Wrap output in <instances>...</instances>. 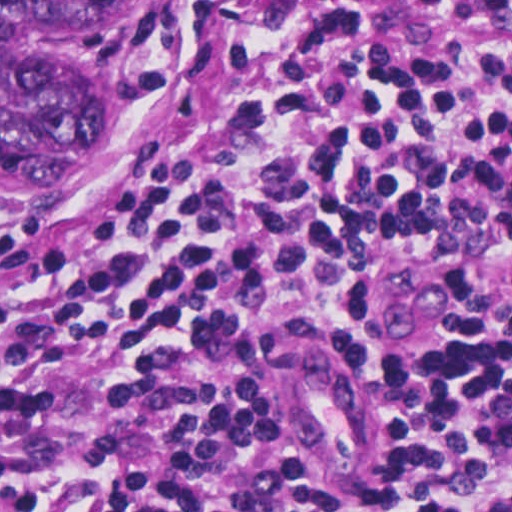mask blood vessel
I'll list each match as a JSON object with an SVG mask.
<instances>
[{"mask_svg":"<svg viewBox=\"0 0 512 512\" xmlns=\"http://www.w3.org/2000/svg\"><path fill=\"white\" fill-rule=\"evenodd\" d=\"M428 268L414 256L370 258L358 282L360 343L376 362L430 365L450 336L449 314ZM488 283L512 289V230L482 253ZM283 408L324 472L352 468L364 435V383L339 353L303 347L280 374Z\"/></svg>","mask_w":512,"mask_h":512,"instance_id":"1","label":"blood vessel"}]
</instances>
